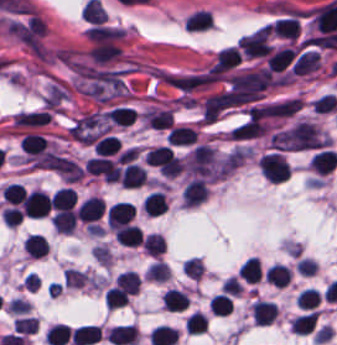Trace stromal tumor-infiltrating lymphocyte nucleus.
I'll return each mask as SVG.
<instances>
[{"label": "stromal tumor-infiltrating lymphocyte nucleus", "instance_id": "bc302bb0", "mask_svg": "<svg viewBox=\"0 0 337 345\" xmlns=\"http://www.w3.org/2000/svg\"><path fill=\"white\" fill-rule=\"evenodd\" d=\"M258 169L262 177L270 182L282 183L289 179L290 167L279 153H265L258 161Z\"/></svg>", "mask_w": 337, "mask_h": 345}, {"label": "stromal tumor-infiltrating lymphocyte nucleus", "instance_id": "52c7bb5b", "mask_svg": "<svg viewBox=\"0 0 337 345\" xmlns=\"http://www.w3.org/2000/svg\"><path fill=\"white\" fill-rule=\"evenodd\" d=\"M183 32L204 34L215 27L212 9L197 7L183 17L181 22Z\"/></svg>", "mask_w": 337, "mask_h": 345}, {"label": "stromal tumor-infiltrating lymphocyte nucleus", "instance_id": "3290ff9b", "mask_svg": "<svg viewBox=\"0 0 337 345\" xmlns=\"http://www.w3.org/2000/svg\"><path fill=\"white\" fill-rule=\"evenodd\" d=\"M240 59L241 54L238 48L227 47L218 50L209 72L212 75H220L240 64Z\"/></svg>", "mask_w": 337, "mask_h": 345}, {"label": "stromal tumor-infiltrating lymphocyte nucleus", "instance_id": "abfb95fc", "mask_svg": "<svg viewBox=\"0 0 337 345\" xmlns=\"http://www.w3.org/2000/svg\"><path fill=\"white\" fill-rule=\"evenodd\" d=\"M133 210L127 203H114L106 209V227L119 228L129 224Z\"/></svg>", "mask_w": 337, "mask_h": 345}, {"label": "stromal tumor-infiltrating lymphocyte nucleus", "instance_id": "9ea309e8", "mask_svg": "<svg viewBox=\"0 0 337 345\" xmlns=\"http://www.w3.org/2000/svg\"><path fill=\"white\" fill-rule=\"evenodd\" d=\"M27 218L38 219L49 209V198L39 190L26 194Z\"/></svg>", "mask_w": 337, "mask_h": 345}, {"label": "stromal tumor-infiltrating lymphocyte nucleus", "instance_id": "f3e2335f", "mask_svg": "<svg viewBox=\"0 0 337 345\" xmlns=\"http://www.w3.org/2000/svg\"><path fill=\"white\" fill-rule=\"evenodd\" d=\"M296 52L292 48H279L271 50L265 60L266 69L271 72H281L287 68Z\"/></svg>", "mask_w": 337, "mask_h": 345}, {"label": "stromal tumor-infiltrating lymphocyte nucleus", "instance_id": "4f13568d", "mask_svg": "<svg viewBox=\"0 0 337 345\" xmlns=\"http://www.w3.org/2000/svg\"><path fill=\"white\" fill-rule=\"evenodd\" d=\"M269 32L278 38L294 39L298 32L296 17L276 19L266 27Z\"/></svg>", "mask_w": 337, "mask_h": 345}, {"label": "stromal tumor-infiltrating lymphocyte nucleus", "instance_id": "2a367800", "mask_svg": "<svg viewBox=\"0 0 337 345\" xmlns=\"http://www.w3.org/2000/svg\"><path fill=\"white\" fill-rule=\"evenodd\" d=\"M104 203L95 197H88L76 210L75 219L83 222H93L102 213Z\"/></svg>", "mask_w": 337, "mask_h": 345}, {"label": "stromal tumor-infiltrating lymphocyte nucleus", "instance_id": "4803ca6d", "mask_svg": "<svg viewBox=\"0 0 337 345\" xmlns=\"http://www.w3.org/2000/svg\"><path fill=\"white\" fill-rule=\"evenodd\" d=\"M207 196V188L200 179H193L187 183L181 198L183 206H194Z\"/></svg>", "mask_w": 337, "mask_h": 345}, {"label": "stromal tumor-infiltrating lymphocyte nucleus", "instance_id": "4245b91a", "mask_svg": "<svg viewBox=\"0 0 337 345\" xmlns=\"http://www.w3.org/2000/svg\"><path fill=\"white\" fill-rule=\"evenodd\" d=\"M118 180L123 187L140 188L146 182L145 171L135 164H128Z\"/></svg>", "mask_w": 337, "mask_h": 345}, {"label": "stromal tumor-infiltrating lymphocyte nucleus", "instance_id": "4c9ddf68", "mask_svg": "<svg viewBox=\"0 0 337 345\" xmlns=\"http://www.w3.org/2000/svg\"><path fill=\"white\" fill-rule=\"evenodd\" d=\"M274 303L255 301L250 314L252 322L259 325H269L275 317Z\"/></svg>", "mask_w": 337, "mask_h": 345}, {"label": "stromal tumor-infiltrating lymphocyte nucleus", "instance_id": "2761f720", "mask_svg": "<svg viewBox=\"0 0 337 345\" xmlns=\"http://www.w3.org/2000/svg\"><path fill=\"white\" fill-rule=\"evenodd\" d=\"M104 117L115 126H130L136 117V110L127 106H114Z\"/></svg>", "mask_w": 337, "mask_h": 345}, {"label": "stromal tumor-infiltrating lymphocyte nucleus", "instance_id": "3c572f05", "mask_svg": "<svg viewBox=\"0 0 337 345\" xmlns=\"http://www.w3.org/2000/svg\"><path fill=\"white\" fill-rule=\"evenodd\" d=\"M337 163V153L323 150L311 157L310 165L315 173L327 174Z\"/></svg>", "mask_w": 337, "mask_h": 345}, {"label": "stromal tumor-infiltrating lymphocyte nucleus", "instance_id": "42bb06b2", "mask_svg": "<svg viewBox=\"0 0 337 345\" xmlns=\"http://www.w3.org/2000/svg\"><path fill=\"white\" fill-rule=\"evenodd\" d=\"M141 209L146 216L157 217L167 209L163 195L160 192H152L142 199Z\"/></svg>", "mask_w": 337, "mask_h": 345}, {"label": "stromal tumor-infiltrating lymphocyte nucleus", "instance_id": "9e4306bb", "mask_svg": "<svg viewBox=\"0 0 337 345\" xmlns=\"http://www.w3.org/2000/svg\"><path fill=\"white\" fill-rule=\"evenodd\" d=\"M195 139H197V135L192 127L172 126L168 130L166 142L171 146H179Z\"/></svg>", "mask_w": 337, "mask_h": 345}, {"label": "stromal tumor-infiltrating lymphocyte nucleus", "instance_id": "04cf8593", "mask_svg": "<svg viewBox=\"0 0 337 345\" xmlns=\"http://www.w3.org/2000/svg\"><path fill=\"white\" fill-rule=\"evenodd\" d=\"M114 239L123 247H137L142 241L138 228L127 224L114 231Z\"/></svg>", "mask_w": 337, "mask_h": 345}, {"label": "stromal tumor-infiltrating lymphocyte nucleus", "instance_id": "e9af9c67", "mask_svg": "<svg viewBox=\"0 0 337 345\" xmlns=\"http://www.w3.org/2000/svg\"><path fill=\"white\" fill-rule=\"evenodd\" d=\"M22 251L32 258H39L47 255L48 244L37 234H30L22 241Z\"/></svg>", "mask_w": 337, "mask_h": 345}, {"label": "stromal tumor-infiltrating lymphocyte nucleus", "instance_id": "782c7336", "mask_svg": "<svg viewBox=\"0 0 337 345\" xmlns=\"http://www.w3.org/2000/svg\"><path fill=\"white\" fill-rule=\"evenodd\" d=\"M53 228L59 234H70L75 227L76 217L75 213L70 209L57 212L51 219Z\"/></svg>", "mask_w": 337, "mask_h": 345}, {"label": "stromal tumor-infiltrating lymphocyte nucleus", "instance_id": "cac63f63", "mask_svg": "<svg viewBox=\"0 0 337 345\" xmlns=\"http://www.w3.org/2000/svg\"><path fill=\"white\" fill-rule=\"evenodd\" d=\"M49 201L52 209H72L75 201L74 192L69 187H62L51 195Z\"/></svg>", "mask_w": 337, "mask_h": 345}, {"label": "stromal tumor-infiltrating lymphocyte nucleus", "instance_id": "2e467ee5", "mask_svg": "<svg viewBox=\"0 0 337 345\" xmlns=\"http://www.w3.org/2000/svg\"><path fill=\"white\" fill-rule=\"evenodd\" d=\"M18 145L22 152L38 156L47 146L42 136L38 133H25Z\"/></svg>", "mask_w": 337, "mask_h": 345}, {"label": "stromal tumor-infiltrating lymphocyte nucleus", "instance_id": "7eef579d", "mask_svg": "<svg viewBox=\"0 0 337 345\" xmlns=\"http://www.w3.org/2000/svg\"><path fill=\"white\" fill-rule=\"evenodd\" d=\"M238 278L245 282H259L260 268L255 257H248L238 268Z\"/></svg>", "mask_w": 337, "mask_h": 345}, {"label": "stromal tumor-infiltrating lymphocyte nucleus", "instance_id": "c26a33f6", "mask_svg": "<svg viewBox=\"0 0 337 345\" xmlns=\"http://www.w3.org/2000/svg\"><path fill=\"white\" fill-rule=\"evenodd\" d=\"M264 276L273 287L281 288L289 282L290 272L289 269H287L286 267L276 264L270 266L265 271Z\"/></svg>", "mask_w": 337, "mask_h": 345}, {"label": "stromal tumor-infiltrating lymphocyte nucleus", "instance_id": "3e0999b9", "mask_svg": "<svg viewBox=\"0 0 337 345\" xmlns=\"http://www.w3.org/2000/svg\"><path fill=\"white\" fill-rule=\"evenodd\" d=\"M316 319L317 316L313 311L302 314L291 319L290 328L297 334H308L312 330Z\"/></svg>", "mask_w": 337, "mask_h": 345}, {"label": "stromal tumor-infiltrating lymphocyte nucleus", "instance_id": "a0a3295f", "mask_svg": "<svg viewBox=\"0 0 337 345\" xmlns=\"http://www.w3.org/2000/svg\"><path fill=\"white\" fill-rule=\"evenodd\" d=\"M165 241L161 235L149 234L144 238L142 250L151 257H158L163 253Z\"/></svg>", "mask_w": 337, "mask_h": 345}, {"label": "stromal tumor-infiltrating lymphocyte nucleus", "instance_id": "b6af03f8", "mask_svg": "<svg viewBox=\"0 0 337 345\" xmlns=\"http://www.w3.org/2000/svg\"><path fill=\"white\" fill-rule=\"evenodd\" d=\"M208 307L212 313L225 317L231 313V299L224 293H217L208 302Z\"/></svg>", "mask_w": 337, "mask_h": 345}, {"label": "stromal tumor-infiltrating lymphocyte nucleus", "instance_id": "6c763739", "mask_svg": "<svg viewBox=\"0 0 337 345\" xmlns=\"http://www.w3.org/2000/svg\"><path fill=\"white\" fill-rule=\"evenodd\" d=\"M320 296L315 288H307L299 292L296 304L301 309L313 310L318 306Z\"/></svg>", "mask_w": 337, "mask_h": 345}, {"label": "stromal tumor-infiltrating lymphocyte nucleus", "instance_id": "fa64b396", "mask_svg": "<svg viewBox=\"0 0 337 345\" xmlns=\"http://www.w3.org/2000/svg\"><path fill=\"white\" fill-rule=\"evenodd\" d=\"M165 307L170 311H183L186 308L187 296L173 289L164 293Z\"/></svg>", "mask_w": 337, "mask_h": 345}, {"label": "stromal tumor-infiltrating lymphocyte nucleus", "instance_id": "21d57d70", "mask_svg": "<svg viewBox=\"0 0 337 345\" xmlns=\"http://www.w3.org/2000/svg\"><path fill=\"white\" fill-rule=\"evenodd\" d=\"M183 325L187 334H200L207 328V318L200 312H193Z\"/></svg>", "mask_w": 337, "mask_h": 345}, {"label": "stromal tumor-infiltrating lymphocyte nucleus", "instance_id": "02f42fee", "mask_svg": "<svg viewBox=\"0 0 337 345\" xmlns=\"http://www.w3.org/2000/svg\"><path fill=\"white\" fill-rule=\"evenodd\" d=\"M120 142L116 137L106 136L94 143V152L100 156H109L119 148Z\"/></svg>", "mask_w": 337, "mask_h": 345}]
</instances>
